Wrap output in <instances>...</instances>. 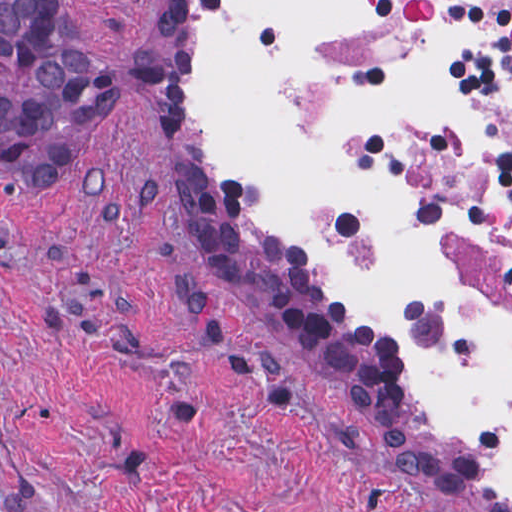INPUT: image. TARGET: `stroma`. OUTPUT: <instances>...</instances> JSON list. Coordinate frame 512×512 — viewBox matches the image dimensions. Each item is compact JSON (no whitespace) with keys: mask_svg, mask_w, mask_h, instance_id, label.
Masks as SVG:
<instances>
[{"mask_svg":"<svg viewBox=\"0 0 512 512\" xmlns=\"http://www.w3.org/2000/svg\"><path fill=\"white\" fill-rule=\"evenodd\" d=\"M58 1L164 69L53 181L0 167V512H512L201 169L202 0Z\"/></svg>","mask_w":512,"mask_h":512,"instance_id":"35a3bbf8","label":"stroma"}]
</instances>
